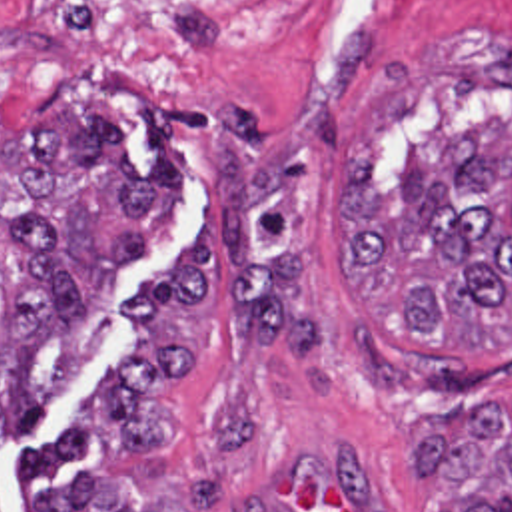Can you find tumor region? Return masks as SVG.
Segmentation results:
<instances>
[{
  "mask_svg": "<svg viewBox=\"0 0 512 512\" xmlns=\"http://www.w3.org/2000/svg\"><path fill=\"white\" fill-rule=\"evenodd\" d=\"M184 209L164 125L132 165L106 105L64 95L0 139V444L24 436L114 325L118 273L152 255ZM344 281L400 335L444 345L512 339V123L404 145L396 185L364 139L344 173ZM414 472L440 482L428 512H512V401L434 420ZM0 512L2 502L0 498ZM32 512H178L104 470L38 492ZM242 512H272L250 492Z\"/></svg>",
  "mask_w": 512,
  "mask_h": 512,
  "instance_id": "e687c5a6",
  "label": "tumor region"
}]
</instances>
